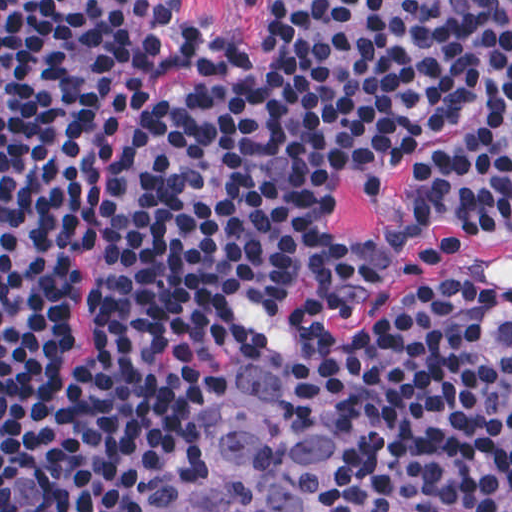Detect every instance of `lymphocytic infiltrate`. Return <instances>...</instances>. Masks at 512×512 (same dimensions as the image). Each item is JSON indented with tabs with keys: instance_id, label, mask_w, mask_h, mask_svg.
Instances as JSON below:
<instances>
[{
	"instance_id": "1",
	"label": "lymphocytic infiltrate",
	"mask_w": 512,
	"mask_h": 512,
	"mask_svg": "<svg viewBox=\"0 0 512 512\" xmlns=\"http://www.w3.org/2000/svg\"><path fill=\"white\" fill-rule=\"evenodd\" d=\"M271 55L195 43L182 0H0V512H166L228 359L319 325L368 512H512V279L332 224L424 141L411 234L512 241V0H243ZM96 254L91 349L58 373Z\"/></svg>"
}]
</instances>
